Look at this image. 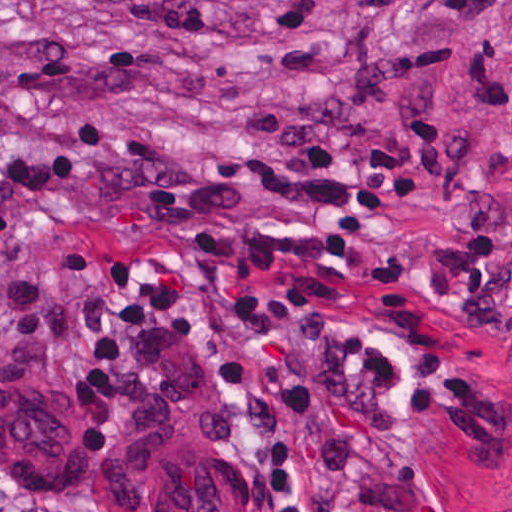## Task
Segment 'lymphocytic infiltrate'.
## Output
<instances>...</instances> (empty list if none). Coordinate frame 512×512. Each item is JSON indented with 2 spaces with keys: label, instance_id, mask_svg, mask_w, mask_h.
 <instances>
[{
  "label": "lymphocytic infiltrate",
  "instance_id": "obj_1",
  "mask_svg": "<svg viewBox=\"0 0 512 512\" xmlns=\"http://www.w3.org/2000/svg\"><path fill=\"white\" fill-rule=\"evenodd\" d=\"M127 322L204 351L238 383L240 452L269 512H394L423 477L392 341L327 310L270 260H166L138 271ZM0 512H95L35 491L0 456Z\"/></svg>",
  "mask_w": 512,
  "mask_h": 512
}]
</instances>
